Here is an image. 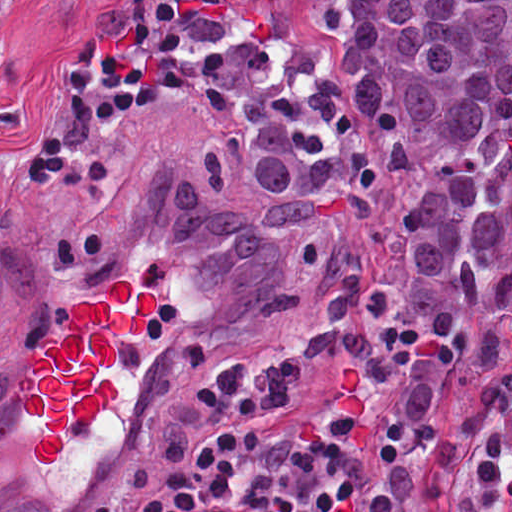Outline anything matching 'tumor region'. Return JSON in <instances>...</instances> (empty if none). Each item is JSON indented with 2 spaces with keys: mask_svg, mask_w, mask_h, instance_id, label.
<instances>
[{
  "mask_svg": "<svg viewBox=\"0 0 512 512\" xmlns=\"http://www.w3.org/2000/svg\"><path fill=\"white\" fill-rule=\"evenodd\" d=\"M190 1L266 219L186 164L150 158L170 245L200 277L214 327L294 314L303 351L353 356L389 415H423L442 372L486 364L512 321V0ZM350 157L362 195L422 171L398 287L369 286L327 206ZM273 226L298 228L305 304ZM449 487L452 512H512V368L380 441L373 512H433Z\"/></svg>",
  "mask_w": 512,
  "mask_h": 512,
  "instance_id": "e687c5a6",
  "label": "tumor region"
}]
</instances>
